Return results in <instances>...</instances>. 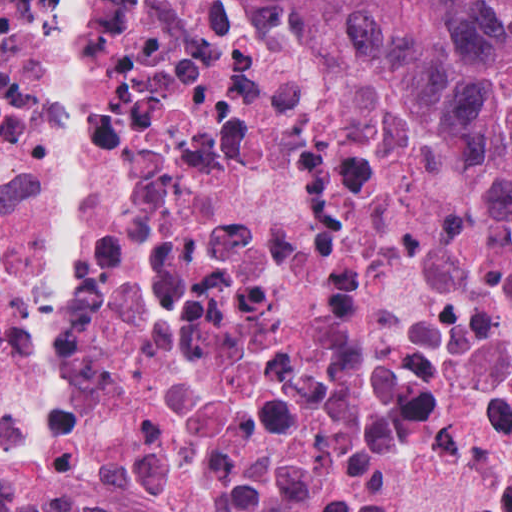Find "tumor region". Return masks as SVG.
<instances>
[{"mask_svg": "<svg viewBox=\"0 0 512 512\" xmlns=\"http://www.w3.org/2000/svg\"><path fill=\"white\" fill-rule=\"evenodd\" d=\"M426 60L480 124L479 179L512 243V0H338Z\"/></svg>", "mask_w": 512, "mask_h": 512, "instance_id": "tumor-region-1", "label": "tumor region"}]
</instances>
